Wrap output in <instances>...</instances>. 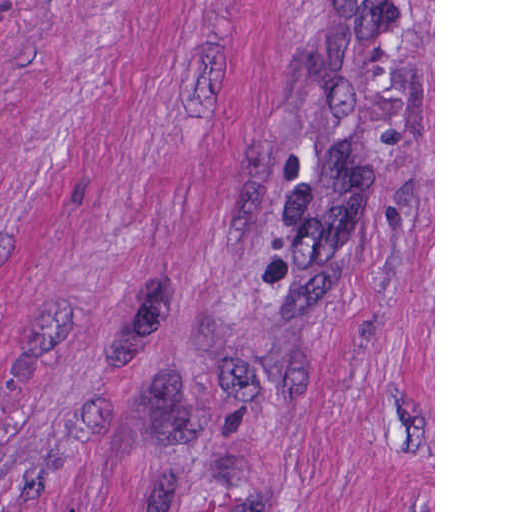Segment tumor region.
I'll return each instance as SVG.
<instances>
[{"instance_id":"e687c5a6","label":"tumor region","mask_w":512,"mask_h":512,"mask_svg":"<svg viewBox=\"0 0 512 512\" xmlns=\"http://www.w3.org/2000/svg\"><path fill=\"white\" fill-rule=\"evenodd\" d=\"M431 192L433 1H326L249 240L254 269L274 289L314 280Z\"/></svg>"}]
</instances>
